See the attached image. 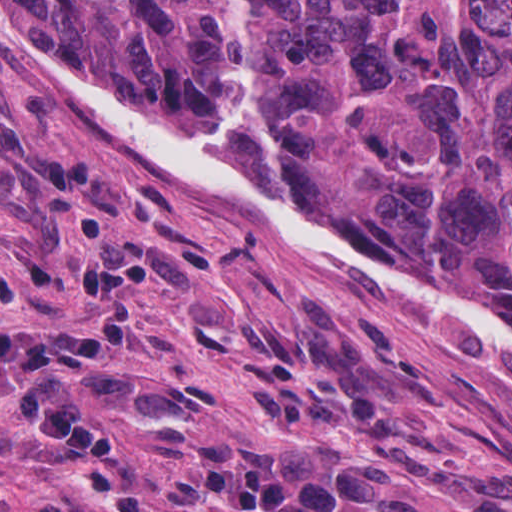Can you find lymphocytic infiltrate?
Segmentation results:
<instances>
[{
	"instance_id": "lymphocytic-infiltrate-1",
	"label": "lymphocytic infiltrate",
	"mask_w": 512,
	"mask_h": 512,
	"mask_svg": "<svg viewBox=\"0 0 512 512\" xmlns=\"http://www.w3.org/2000/svg\"><path fill=\"white\" fill-rule=\"evenodd\" d=\"M162 273L173 285L184 273L162 251L130 243L96 247L76 284L98 335L87 345L55 326L0 323V396L23 411L41 441L90 459L99 490L113 512H376L391 485L397 454L391 439L361 451L333 449L312 456L302 448L263 447L204 433L181 460L175 486L188 504L134 481L118 454L119 435L76 390L125 397L135 409H170L187 381L134 373L110 351L138 336L134 283ZM0 303L21 309L14 274L0 270ZM54 496L0 512H69Z\"/></svg>"
}]
</instances>
